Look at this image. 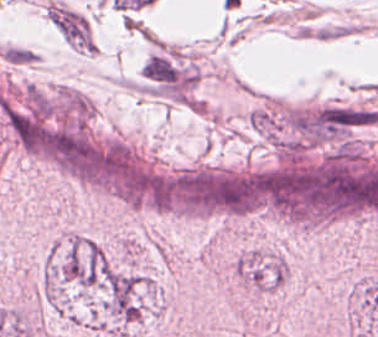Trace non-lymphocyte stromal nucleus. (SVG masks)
<instances>
[{"instance_id": "obj_2", "label": "non-lymphocyte stromal nucleus", "mask_w": 378, "mask_h": 337, "mask_svg": "<svg viewBox=\"0 0 378 337\" xmlns=\"http://www.w3.org/2000/svg\"><path fill=\"white\" fill-rule=\"evenodd\" d=\"M0 53L6 62L14 65H26L36 60V54L24 46L6 45Z\"/></svg>"}, {"instance_id": "obj_1", "label": "non-lymphocyte stromal nucleus", "mask_w": 378, "mask_h": 337, "mask_svg": "<svg viewBox=\"0 0 378 337\" xmlns=\"http://www.w3.org/2000/svg\"><path fill=\"white\" fill-rule=\"evenodd\" d=\"M46 18L68 45L77 51L93 53L91 28L87 19L74 9L55 2L45 5Z\"/></svg>"}]
</instances>
